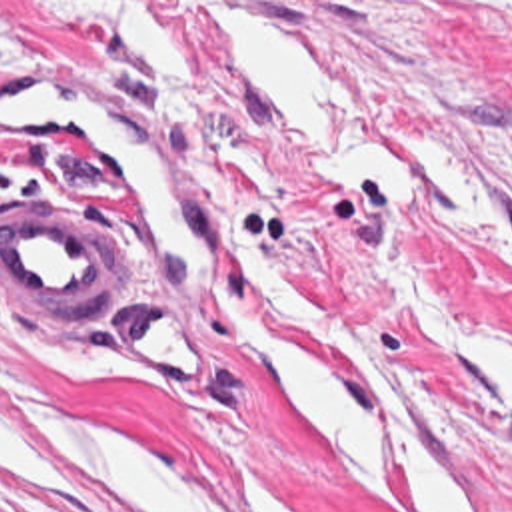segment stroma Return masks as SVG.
<instances>
[{"instance_id":"35a3bbf8","label":"stroma","mask_w":512,"mask_h":512,"mask_svg":"<svg viewBox=\"0 0 512 512\" xmlns=\"http://www.w3.org/2000/svg\"><path fill=\"white\" fill-rule=\"evenodd\" d=\"M216 6L302 34L364 120L422 170V188H370L306 144L234 60ZM5 76L116 94L148 120L278 280L390 359L440 429L474 512H512V0H0ZM41 204H75V218L109 228L114 282L87 305H7L0 294L1 401L188 445L266 512H280L272 479L304 512H380L302 453L254 391L218 309L246 297L282 327L260 296L214 264L208 297L170 299L99 170L0 120V220ZM142 299L196 321L206 381L162 379L126 353L112 321ZM23 417L67 469L43 471L35 489L0 475V512H122L57 415ZM390 479L398 511L412 512Z\"/></svg>"}]
</instances>
